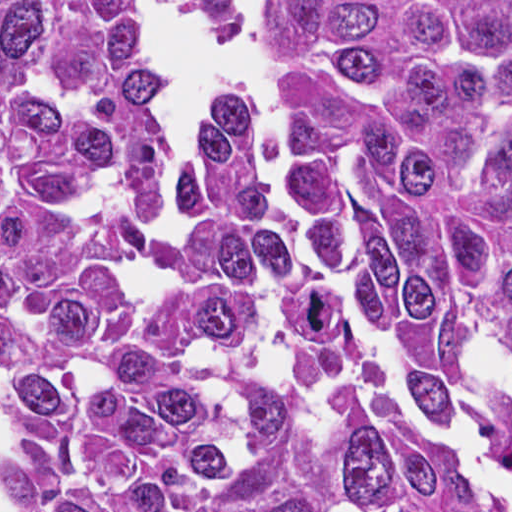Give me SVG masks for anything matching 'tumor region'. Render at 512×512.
<instances>
[{
  "mask_svg": "<svg viewBox=\"0 0 512 512\" xmlns=\"http://www.w3.org/2000/svg\"><path fill=\"white\" fill-rule=\"evenodd\" d=\"M0 0V323L30 512H480L386 396L476 395L512 340V0H257L283 123L242 100L169 192L142 10Z\"/></svg>",
  "mask_w": 512,
  "mask_h": 512,
  "instance_id": "e687c5a6",
  "label": "tumor region"
}]
</instances>
